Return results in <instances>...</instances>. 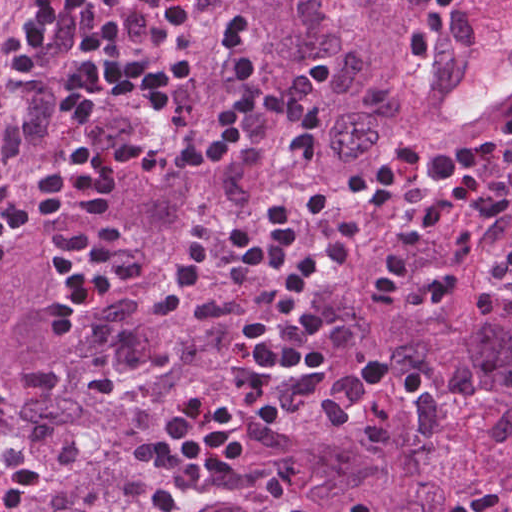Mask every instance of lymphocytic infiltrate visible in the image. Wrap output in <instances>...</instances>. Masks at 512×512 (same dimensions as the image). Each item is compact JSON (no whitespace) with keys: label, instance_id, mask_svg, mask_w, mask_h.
Segmentation results:
<instances>
[{"label":"lymphocytic infiltrate","instance_id":"obj_1","mask_svg":"<svg viewBox=\"0 0 512 512\" xmlns=\"http://www.w3.org/2000/svg\"><path fill=\"white\" fill-rule=\"evenodd\" d=\"M477 0H426L410 44L430 68L454 14ZM185 0H159L150 28L122 25L118 0H79L83 55L97 59L121 44L160 50L157 62L135 51L97 69L45 52L55 11L39 10L10 41L8 57L55 98L72 152L52 181L39 177L24 194L0 198V259L24 236L51 221V264L68 289L59 315L80 316L144 284L143 253L123 239L95 236L96 223L120 196L126 174L142 172L183 184L228 161L244 137L261 86L259 29L232 13L213 39L223 67L214 109L197 125L155 141L105 129L104 110L145 118L168 115L195 77L183 51ZM441 188L470 189L474 209L419 220L376 270L379 294L406 290L416 259L432 242L474 224L512 218V110L497 147L462 144L424 155H375L353 173L342 194V220L332 198L302 195L256 207L234 223L202 226L179 253L152 323L164 333L199 306L212 284L259 280L239 350L242 385L233 392L192 382L154 432L146 450L163 486L198 495L235 468L250 439L290 422L321 395L331 355L310 316L321 293L349 269L368 238L367 223L387 206L416 204ZM512 275V240L498 253ZM352 512H372L355 507ZM450 512H512V485L458 496Z\"/></svg>","mask_w":512,"mask_h":512}]
</instances>
